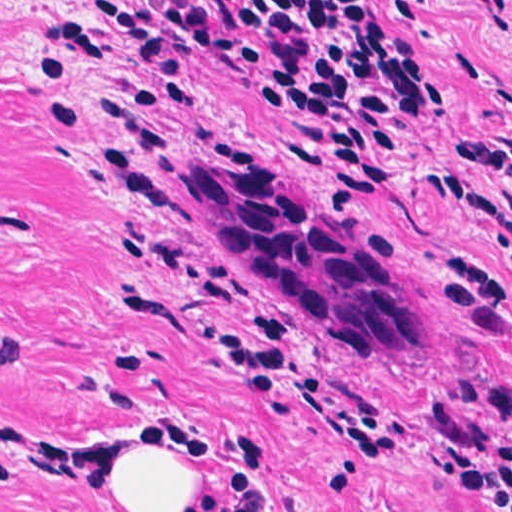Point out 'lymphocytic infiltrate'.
Masks as SVG:
<instances>
[{
  "label": "lymphocytic infiltrate",
  "mask_w": 512,
  "mask_h": 512,
  "mask_svg": "<svg viewBox=\"0 0 512 512\" xmlns=\"http://www.w3.org/2000/svg\"><path fill=\"white\" fill-rule=\"evenodd\" d=\"M482 20L512 29V0H467ZM127 52L122 101L127 113L194 127L204 108L189 82L192 60L226 65L247 98L295 119L275 142L284 165L314 168L353 197L379 195L393 174L399 130L425 111L433 80L406 34L366 0H99ZM60 42L91 63L96 39L75 16L43 41ZM72 70L33 54L38 93ZM66 150L87 122L62 102L47 107ZM460 160L489 170L505 189L457 173L441 175L446 196L470 208L505 239L497 269L479 252L452 255L440 294L487 338L512 337V147L491 140L455 144ZM222 347L300 375V324L290 313L256 309L239 317ZM455 493L452 512H512V435L432 469Z\"/></svg>",
  "instance_id": "obj_1"
}]
</instances>
